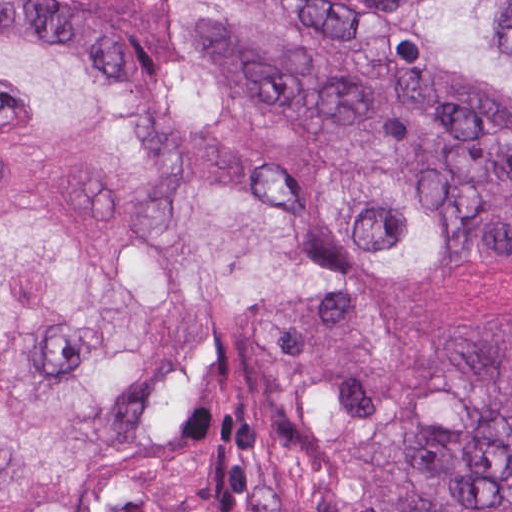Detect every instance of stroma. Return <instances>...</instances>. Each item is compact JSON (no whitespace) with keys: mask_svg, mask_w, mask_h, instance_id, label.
Here are the masks:
<instances>
[{"mask_svg":"<svg viewBox=\"0 0 512 512\" xmlns=\"http://www.w3.org/2000/svg\"><path fill=\"white\" fill-rule=\"evenodd\" d=\"M95 1L135 23L140 57L127 64L5 32L0 41L39 42L77 59L112 96L154 120L170 147L159 229L215 317L217 349L163 395L149 418L138 469L107 482L88 512H383L358 468V449L377 423L413 396L464 409L512 406V245L483 237L469 198L448 182L418 169L354 163L294 136L183 0ZM293 1L363 52L394 94H433L512 117L511 88L425 56L364 1ZM166 22H175L258 141L449 213V253L385 261L366 276L365 314L386 350V372L336 446L301 440L283 377L249 314L182 249V140L166 103Z\"/></svg>","mask_w":512,"mask_h":512,"instance_id":"stroma-1","label":"stroma"}]
</instances>
